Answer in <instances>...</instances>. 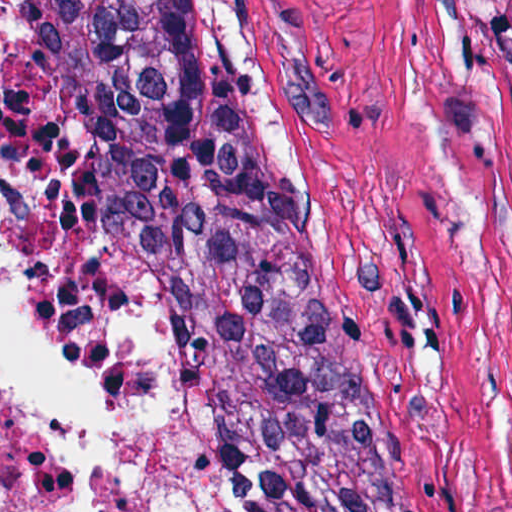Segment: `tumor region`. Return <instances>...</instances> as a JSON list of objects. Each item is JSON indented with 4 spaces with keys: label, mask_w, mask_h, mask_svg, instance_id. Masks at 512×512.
Returning a JSON list of instances; mask_svg holds the SVG:
<instances>
[{
    "label": "tumor region",
    "mask_w": 512,
    "mask_h": 512,
    "mask_svg": "<svg viewBox=\"0 0 512 512\" xmlns=\"http://www.w3.org/2000/svg\"><path fill=\"white\" fill-rule=\"evenodd\" d=\"M24 290L62 348L149 321L227 512H441L247 80L149 1L67 36L35 80Z\"/></svg>",
    "instance_id": "tumor-region-1"
}]
</instances>
